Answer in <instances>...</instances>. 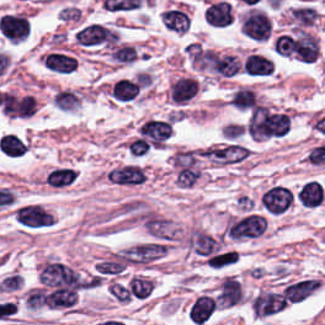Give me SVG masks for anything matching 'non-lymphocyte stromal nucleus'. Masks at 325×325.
I'll use <instances>...</instances> for the list:
<instances>
[{"instance_id":"obj_1","label":"non-lymphocyte stromal nucleus","mask_w":325,"mask_h":325,"mask_svg":"<svg viewBox=\"0 0 325 325\" xmlns=\"http://www.w3.org/2000/svg\"><path fill=\"white\" fill-rule=\"evenodd\" d=\"M288 306L282 290L261 289L250 297V308L257 318H268Z\"/></svg>"},{"instance_id":"obj_2","label":"non-lymphocyte stromal nucleus","mask_w":325,"mask_h":325,"mask_svg":"<svg viewBox=\"0 0 325 325\" xmlns=\"http://www.w3.org/2000/svg\"><path fill=\"white\" fill-rule=\"evenodd\" d=\"M219 310L211 291L193 297L188 309V321L194 325H206Z\"/></svg>"},{"instance_id":"obj_3","label":"non-lymphocyte stromal nucleus","mask_w":325,"mask_h":325,"mask_svg":"<svg viewBox=\"0 0 325 325\" xmlns=\"http://www.w3.org/2000/svg\"><path fill=\"white\" fill-rule=\"evenodd\" d=\"M167 247L162 242H142L121 249L120 258L135 263H148L165 251Z\"/></svg>"},{"instance_id":"obj_4","label":"non-lymphocyte stromal nucleus","mask_w":325,"mask_h":325,"mask_svg":"<svg viewBox=\"0 0 325 325\" xmlns=\"http://www.w3.org/2000/svg\"><path fill=\"white\" fill-rule=\"evenodd\" d=\"M318 289L317 278H304L286 284L283 296L288 301L301 302Z\"/></svg>"},{"instance_id":"obj_5","label":"non-lymphocyte stromal nucleus","mask_w":325,"mask_h":325,"mask_svg":"<svg viewBox=\"0 0 325 325\" xmlns=\"http://www.w3.org/2000/svg\"><path fill=\"white\" fill-rule=\"evenodd\" d=\"M325 195L324 186L317 180H310L298 190V199L304 206L319 207Z\"/></svg>"},{"instance_id":"obj_6","label":"non-lymphocyte stromal nucleus","mask_w":325,"mask_h":325,"mask_svg":"<svg viewBox=\"0 0 325 325\" xmlns=\"http://www.w3.org/2000/svg\"><path fill=\"white\" fill-rule=\"evenodd\" d=\"M82 102L77 90L61 87L54 95V105L65 111H72Z\"/></svg>"},{"instance_id":"obj_7","label":"non-lymphocyte stromal nucleus","mask_w":325,"mask_h":325,"mask_svg":"<svg viewBox=\"0 0 325 325\" xmlns=\"http://www.w3.org/2000/svg\"><path fill=\"white\" fill-rule=\"evenodd\" d=\"M77 173L73 168L55 167L49 174L47 185L63 186L74 181Z\"/></svg>"}]
</instances>
